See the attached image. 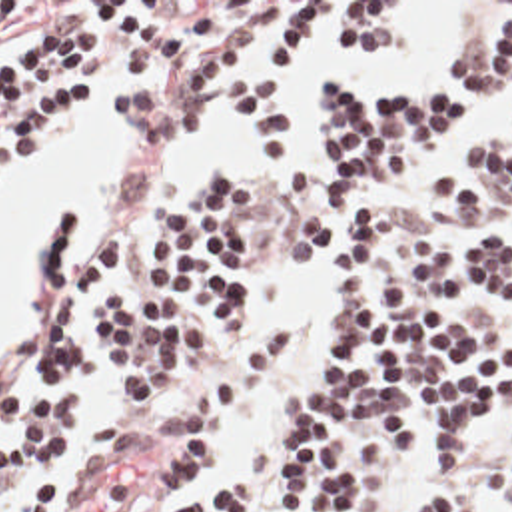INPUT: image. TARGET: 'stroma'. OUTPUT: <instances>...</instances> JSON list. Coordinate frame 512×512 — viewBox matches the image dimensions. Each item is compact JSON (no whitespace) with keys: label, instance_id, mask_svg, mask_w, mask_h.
<instances>
[{"label":"stroma","instance_id":"stroma-1","mask_svg":"<svg viewBox=\"0 0 512 512\" xmlns=\"http://www.w3.org/2000/svg\"><path fill=\"white\" fill-rule=\"evenodd\" d=\"M0 2H17L15 10L11 14V30L15 34L13 42L23 36L43 34L47 30H53L67 22H73L81 16H93L87 2H173L171 8L211 6V8H217V26L213 32L223 30L227 26H231L237 32V50L223 62V66L215 74L207 76L199 86V118L191 130L185 146L177 148V150H141V180H139V184L135 186L133 194L119 208H115L111 214H107L103 218L89 248L83 240V224H81L79 216L71 210L69 204H57L55 208H51L45 214V218L41 220V226H39V236L35 240V248H33V312H31V321H29V355H27V361H25L21 373L0 379V385H13V383L33 375V369H35V321L39 315V254H41L47 220L51 218V214L55 210H59L63 206L69 208V212L75 220V256L81 260H85V256L89 254V250L93 248L97 236L101 234V230L105 226L119 224L127 232L125 256H123L121 264L117 266V270L113 272V276L109 280H105V284H121L123 288L133 290V288H143V286L157 282V266L147 262V244H149V236L153 230L157 210L167 196L179 194V192L191 188L193 184H197L209 164H223L241 184H259L261 188H265V218L257 226L253 240H251V250H249V256L255 264L253 337L267 329H287L285 321H269V319H263L257 312V268H259L261 260H267V258H297L317 270V274H319V321H317L311 337H291L289 359L285 361V365L281 367V371L277 373V377L273 379L269 389L259 399H255L245 411L239 413L235 435L213 455V459L209 463H205L193 471L191 479L187 481V485L183 487V491L177 497L187 495L203 483L207 473L219 461L227 459L239 445L261 435L263 431H267L273 423H277L281 419V415L285 411L287 395L295 383V377L305 367L309 353L321 333L323 317H325V310L329 306L331 288H333V250L329 256H305V254L287 252V248L291 244L293 228L317 190L315 116H313V126H311V154L303 168V184L299 188H295L293 192H279V190L271 188L265 174H261L247 160L207 158V162L203 164L201 170H197L177 182H165L157 202L143 204L147 188L157 172L159 162L165 160L167 156L189 152L197 144L201 132L205 130V126L211 122V118L215 114V90L235 66H237V72H235V100H237V92H239L243 78L255 66L263 64V60L269 52L271 28L277 26L291 12V8L297 2H396V8L406 18H410V34L406 36V40L400 46L410 42L416 36V32L420 30L422 18H424L422 2H484V8L478 16V22L474 26L470 40L464 46H460L444 62L430 64L426 68L398 76L386 84L373 86V88H355L341 80H325V82H331L347 98H365V96L378 94L394 84L420 82V80H428V78L442 74L450 64L468 56L474 50V46L482 40L496 6L500 2H512V0H0ZM315 32H317L319 44L323 48V8L317 12L293 62L281 74V94H283V104L289 114H291L293 92H295V74L299 70L303 56L307 54V50L313 42ZM400 46H396L392 50L376 52V54L394 52ZM376 54L357 56V58H333V60L335 62H355V60L373 58ZM123 80H125V74L117 72L109 90L105 86H99L97 96H95V112L71 120L55 136H51L41 146L29 150L25 156H21L9 168V172L0 186V208L5 204L7 196L13 190H17L23 182H27L33 176V172L47 162V158L63 144V140L77 126L93 122L97 118H105V116H111L127 130H131L137 124V122H121L119 118L113 116L111 106H109V102L117 94ZM317 86H319V82L313 88V96H317ZM237 104H239V100H237ZM243 122H245V118H243ZM245 128L249 132L251 142L261 150L263 156L277 158L285 152V150H263L255 130L247 122H245ZM468 132H512V98L476 102L468 110H464L456 122H452V124L444 126L442 130L416 142V146L406 154V158L392 172L388 182L384 186L376 188L375 194H373V196H384V214H386L390 228H404L406 224H410L414 220V222L426 226L432 240L442 246L478 238V236L490 234V232L508 234L512 238V208H508L502 216H498L494 222L486 224L478 232H460L442 218V214L438 212V208L432 200V174H434V168H436L446 144L450 140H454L456 136L468 134ZM486 312L512 329V304H496ZM237 353H239V347L233 345L231 337L221 327H211L207 357H205V365H203V371H201L197 383L169 411L155 415V413L145 411L131 397V393L125 387H121L115 379H111L107 375L103 337H101L99 329H95V365L91 369L87 389L81 399L83 425H81L77 447L105 431H141V429H147V427L163 421L165 417H169L173 413V409L179 403L189 399L201 385H205L213 377H217ZM418 431H420V427L414 429L412 457L396 479L390 512H414L424 485L434 475H456L458 479H462L466 483L472 505L476 509L484 512H500L506 497H508L510 483H512V421L500 419L488 427L478 429L468 447L464 461L454 471H448V473H440L424 461V457L420 455ZM3 437H5V433L0 429V445ZM167 457H169V453L163 449H157L147 455V469L137 485V491L133 495V501H131L127 512H165V509L169 507L171 501H161V495H159L161 473L167 465ZM57 512H59V489H57Z\"/></svg>","mask_w":512,"mask_h":512}]
</instances>
